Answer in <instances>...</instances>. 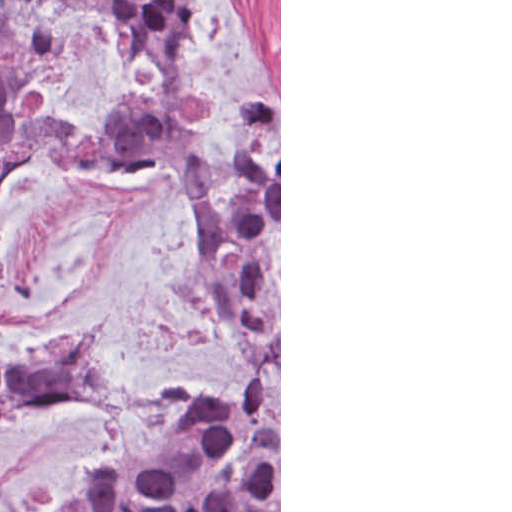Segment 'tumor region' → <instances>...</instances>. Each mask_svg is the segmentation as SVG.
Wrapping results in <instances>:
<instances>
[{
    "instance_id": "obj_1",
    "label": "tumor region",
    "mask_w": 512,
    "mask_h": 512,
    "mask_svg": "<svg viewBox=\"0 0 512 512\" xmlns=\"http://www.w3.org/2000/svg\"><path fill=\"white\" fill-rule=\"evenodd\" d=\"M86 8L105 19L116 57L141 44L158 71L161 101L123 100L101 130L80 133L44 113L41 49L9 28L40 11ZM0 0V76L20 96L14 136L0 146V193L39 146L83 169L130 159L176 165L196 186V273L209 301L230 303L242 337V372L223 393L190 391L165 414V451L114 456L89 467L63 512H279V101L252 116L226 174H212L187 129L204 119L185 91L179 36L194 29L196 0ZM95 329L45 348L28 365L0 364V463L10 427L46 410L115 399Z\"/></svg>"
}]
</instances>
